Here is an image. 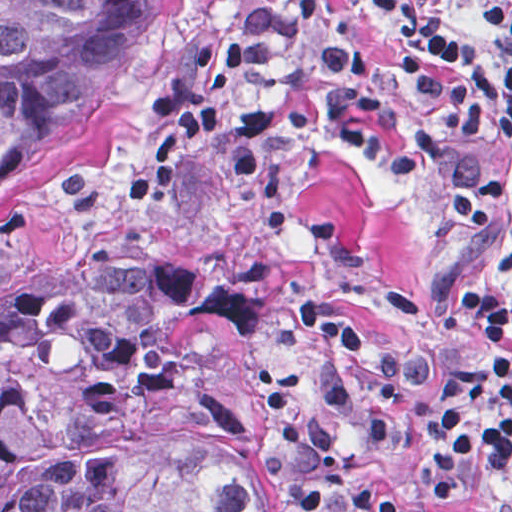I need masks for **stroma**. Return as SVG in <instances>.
<instances>
[{
    "mask_svg": "<svg viewBox=\"0 0 512 512\" xmlns=\"http://www.w3.org/2000/svg\"><path fill=\"white\" fill-rule=\"evenodd\" d=\"M465 36L488 6L512 0H419ZM364 55L389 56L396 26L379 0H340ZM254 0H154L138 21L104 141L61 191L0 211V279L108 250H168L263 296L244 313L196 316V345L238 398V445L260 512H310L278 433L273 394L313 382L326 349L294 322L302 287L341 301L373 343L403 365L393 423L365 467L395 489L423 485L426 406L440 383L397 341L471 348L512 366V351L444 293V269L512 282V197L482 206L488 230L433 208L450 186L512 168V145L436 156L412 171L382 163L330 129L241 134L249 112L322 96L320 56L296 66L234 60ZM353 287L397 340L356 303ZM505 512L502 467L480 452L430 509Z\"/></svg>",
    "mask_w": 512,
    "mask_h": 512,
    "instance_id": "obj_1",
    "label": "stroma"
}]
</instances>
